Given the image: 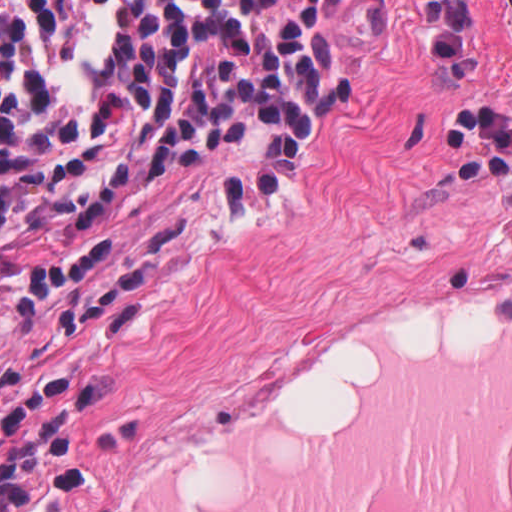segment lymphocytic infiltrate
I'll return each mask as SVG.
<instances>
[{
    "label": "lymphocytic infiltrate",
    "instance_id": "obj_1",
    "mask_svg": "<svg viewBox=\"0 0 512 512\" xmlns=\"http://www.w3.org/2000/svg\"><path fill=\"white\" fill-rule=\"evenodd\" d=\"M346 99L339 0H0V262L248 118L274 139L234 185L251 206Z\"/></svg>",
    "mask_w": 512,
    "mask_h": 512
}]
</instances>
